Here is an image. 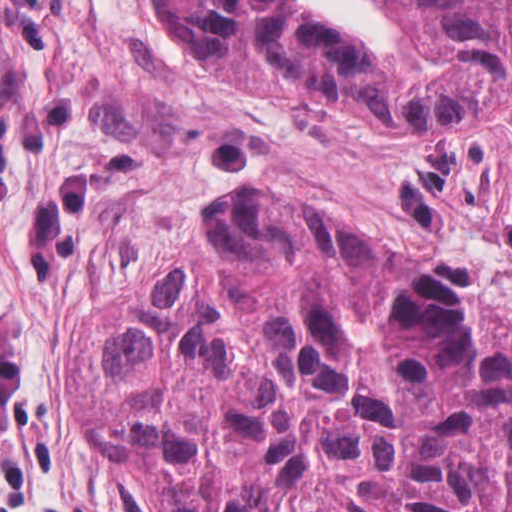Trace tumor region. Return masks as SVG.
<instances>
[{
    "instance_id": "obj_1",
    "label": "tumor region",
    "mask_w": 512,
    "mask_h": 512,
    "mask_svg": "<svg viewBox=\"0 0 512 512\" xmlns=\"http://www.w3.org/2000/svg\"><path fill=\"white\" fill-rule=\"evenodd\" d=\"M251 95L434 128L512 87V0H379L360 54L301 0H155ZM74 323V433L150 512H512V370L459 272L261 187Z\"/></svg>"
}]
</instances>
